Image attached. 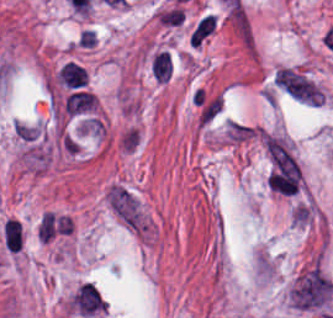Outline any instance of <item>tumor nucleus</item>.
I'll return each mask as SVG.
<instances>
[{
    "mask_svg": "<svg viewBox=\"0 0 333 318\" xmlns=\"http://www.w3.org/2000/svg\"><path fill=\"white\" fill-rule=\"evenodd\" d=\"M1 240L14 244L22 248V241H23V231L22 226L0 233Z\"/></svg>",
    "mask_w": 333,
    "mask_h": 318,
    "instance_id": "tumor-nucleus-1",
    "label": "tumor nucleus"
}]
</instances>
